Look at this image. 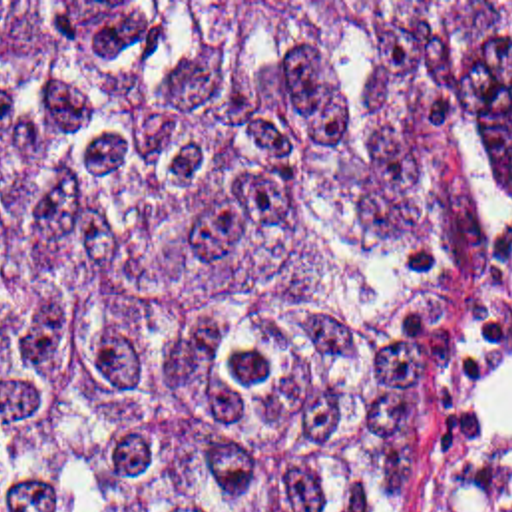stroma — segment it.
I'll return each instance as SVG.
<instances>
[{
  "label": "stroma",
  "instance_id": "1",
  "mask_svg": "<svg viewBox=\"0 0 512 512\" xmlns=\"http://www.w3.org/2000/svg\"><path fill=\"white\" fill-rule=\"evenodd\" d=\"M373 2L468 78L480 36L512 0H0ZM415 512H512V199L468 177V227L451 307V402Z\"/></svg>",
  "mask_w": 512,
  "mask_h": 512
}]
</instances>
